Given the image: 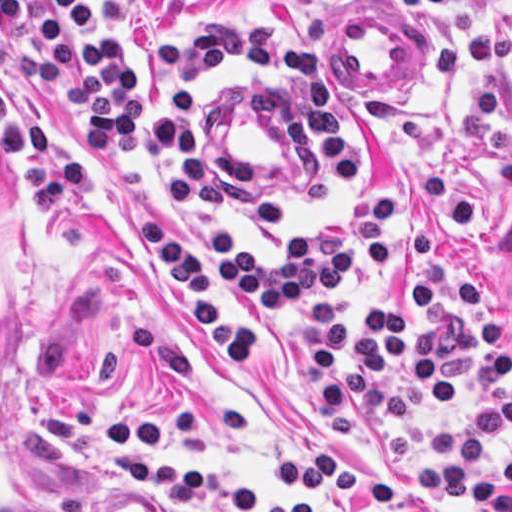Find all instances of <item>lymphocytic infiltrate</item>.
<instances>
[{
	"mask_svg": "<svg viewBox=\"0 0 512 512\" xmlns=\"http://www.w3.org/2000/svg\"><path fill=\"white\" fill-rule=\"evenodd\" d=\"M293 1L317 13L318 0ZM487 1L394 0L405 14L465 11L464 41L435 51L440 82L511 60V41L469 8ZM211 65L299 88L302 187L317 200H336L358 186L360 134L315 57L269 26L202 23L187 35L159 37L149 53L128 42L123 0H0V141L36 216L60 215L93 176L92 165L43 136L30 110V99L43 93L75 99L76 139L90 156H134L164 143L187 211L217 208L228 177L192 135L194 78ZM493 180L496 191L512 193V128ZM397 215L396 198H368L310 226L280 256L254 254L247 230L236 225L212 236L207 249L160 237L142 218L141 246L172 277L200 341L225 359L263 414L281 422L260 374L303 316V374L321 415L356 406L364 422L385 429L438 401H463L471 419L426 433L409 475L447 499H472L479 512H512L511 326L470 274L441 260L437 235L411 232L396 247ZM281 423L300 443L296 451L263 440L248 416L223 411L192 423L177 400L122 414L110 429L165 453L260 446L276 481L296 486L290 497L200 476L182 463L120 459L113 466L161 512H333L355 498L374 512H430L377 476L340 470L326 441Z\"/></svg>",
	"mask_w": 512,
	"mask_h": 512,
	"instance_id": "lymphocytic-infiltrate-1",
	"label": "lymphocytic infiltrate"
}]
</instances>
